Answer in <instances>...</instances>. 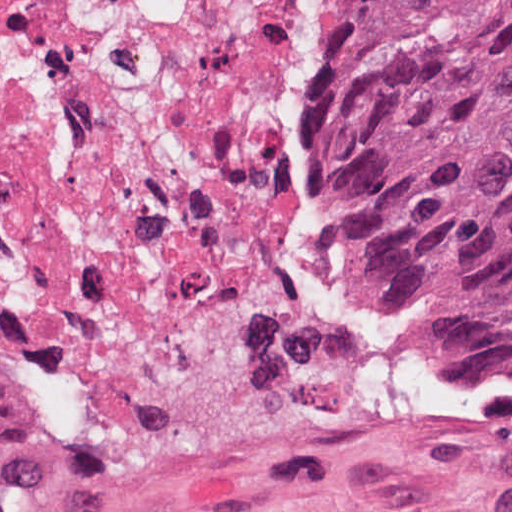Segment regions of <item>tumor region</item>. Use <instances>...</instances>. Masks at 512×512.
Instances as JSON below:
<instances>
[{
	"label": "tumor region",
	"instance_id": "e687c5a6",
	"mask_svg": "<svg viewBox=\"0 0 512 512\" xmlns=\"http://www.w3.org/2000/svg\"><path fill=\"white\" fill-rule=\"evenodd\" d=\"M350 213L380 279L512 357V0H371ZM40 441L41 414L0 356V465Z\"/></svg>",
	"mask_w": 512,
	"mask_h": 512
}]
</instances>
